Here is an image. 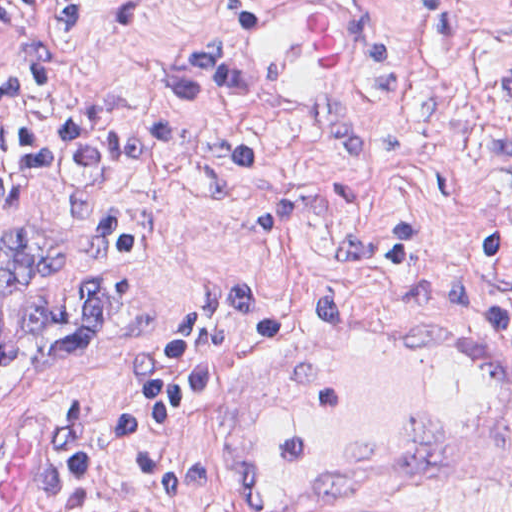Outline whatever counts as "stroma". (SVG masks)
I'll return each mask as SVG.
<instances>
[{"label":"stroma","mask_w":512,"mask_h":512,"mask_svg":"<svg viewBox=\"0 0 512 512\" xmlns=\"http://www.w3.org/2000/svg\"><path fill=\"white\" fill-rule=\"evenodd\" d=\"M266 0H94L91 40L54 77L73 110L107 82L190 133L162 171L36 166L0 219V512L46 484L53 415L79 398L102 467L84 508L234 512L261 340L235 383L174 430L224 458L218 507L129 504L110 436L144 357L190 295L240 278L284 310L287 334L326 311L450 322L512 351V0H331L366 38L354 92L281 109L242 75L233 37ZM59 0L37 24L56 47ZM19 36L0 24V82ZM10 211L0 214H6ZM183 427V428H182ZM390 512H512V463L455 499Z\"/></svg>","instance_id":"stroma-1"}]
</instances>
